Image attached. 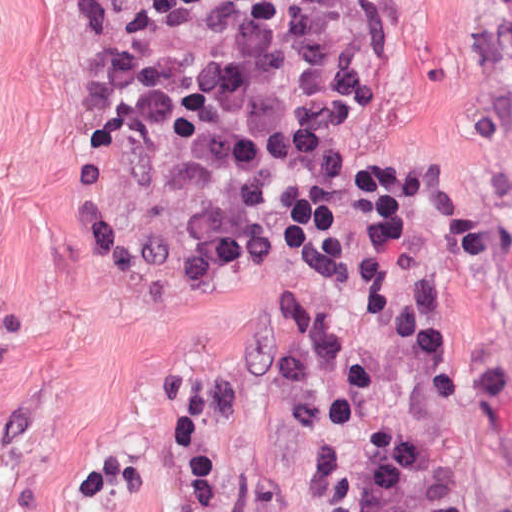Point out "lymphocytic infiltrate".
Wrapping results in <instances>:
<instances>
[{"label": "lymphocytic infiltrate", "mask_w": 512, "mask_h": 512, "mask_svg": "<svg viewBox=\"0 0 512 512\" xmlns=\"http://www.w3.org/2000/svg\"><path fill=\"white\" fill-rule=\"evenodd\" d=\"M401 0H100L96 42L137 130L215 143L232 223L303 289L367 512H512V372L437 334L395 190L303 124L386 92Z\"/></svg>", "instance_id": "f902f5d3"}]
</instances>
